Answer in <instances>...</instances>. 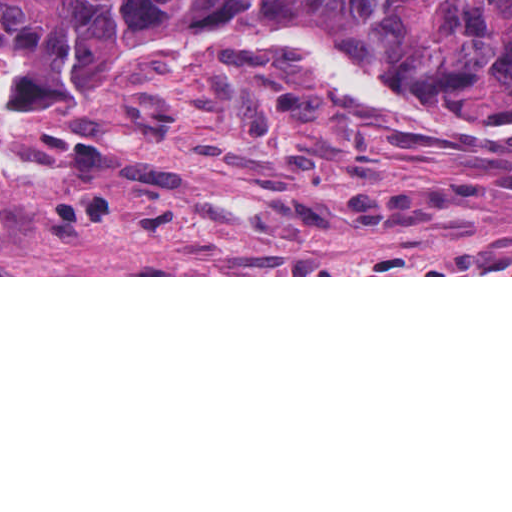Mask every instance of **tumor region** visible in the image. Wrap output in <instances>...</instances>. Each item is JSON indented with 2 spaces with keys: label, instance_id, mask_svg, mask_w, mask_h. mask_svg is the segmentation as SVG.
<instances>
[{
  "label": "tumor region",
  "instance_id": "e687c5a6",
  "mask_svg": "<svg viewBox=\"0 0 512 512\" xmlns=\"http://www.w3.org/2000/svg\"><path fill=\"white\" fill-rule=\"evenodd\" d=\"M218 20L309 50L394 103L512 131V0H0V124L79 114L162 39Z\"/></svg>",
  "mask_w": 512,
  "mask_h": 512
}]
</instances>
